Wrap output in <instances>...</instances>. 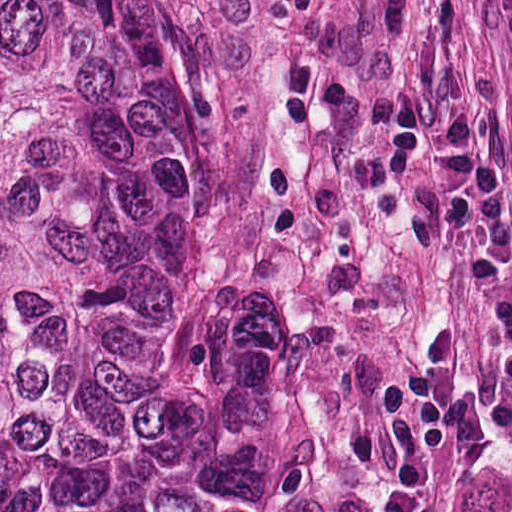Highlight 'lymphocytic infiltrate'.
<instances>
[{"mask_svg":"<svg viewBox=\"0 0 512 512\" xmlns=\"http://www.w3.org/2000/svg\"><path fill=\"white\" fill-rule=\"evenodd\" d=\"M384 161L399 179L418 178L409 155L434 168L450 241L462 255L469 288L493 333L502 364L483 410L458 387L462 341L444 315L418 316L409 363L383 378L382 389L409 430L431 451L466 458L483 440L484 422L512 449V211L487 130L457 111L435 119L408 95L392 94Z\"/></svg>","mask_w":512,"mask_h":512,"instance_id":"obj_1","label":"lymphocytic infiltrate"}]
</instances>
